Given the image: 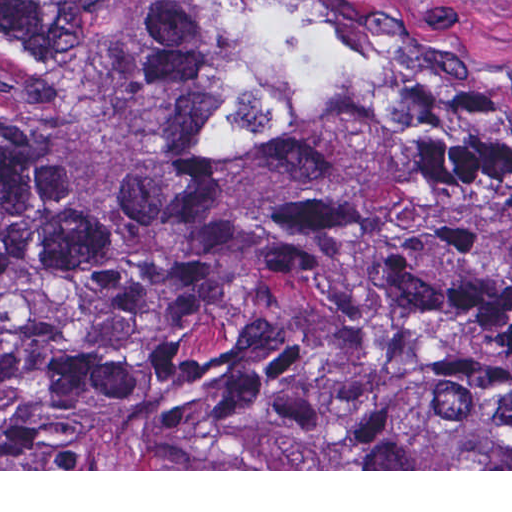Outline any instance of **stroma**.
<instances>
[{"instance_id":"1","label":"stroma","mask_w":512,"mask_h":512,"mask_svg":"<svg viewBox=\"0 0 512 512\" xmlns=\"http://www.w3.org/2000/svg\"><path fill=\"white\" fill-rule=\"evenodd\" d=\"M322 32L379 85L512 120V0H244ZM0 471H512V469H0Z\"/></svg>"}]
</instances>
